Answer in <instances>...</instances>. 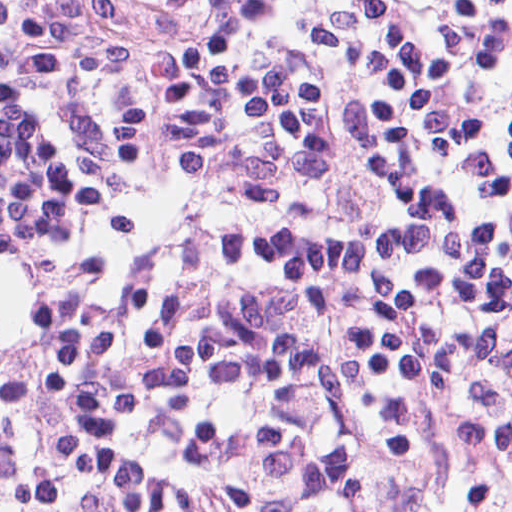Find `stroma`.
I'll list each match as a JSON object with an SVG mask.
<instances>
[{
    "mask_svg": "<svg viewBox=\"0 0 512 512\" xmlns=\"http://www.w3.org/2000/svg\"><path fill=\"white\" fill-rule=\"evenodd\" d=\"M412 512H512V354L475 431L436 465L432 488Z\"/></svg>",
    "mask_w": 512,
    "mask_h": 512,
    "instance_id": "obj_1",
    "label": "stroma"
}]
</instances>
